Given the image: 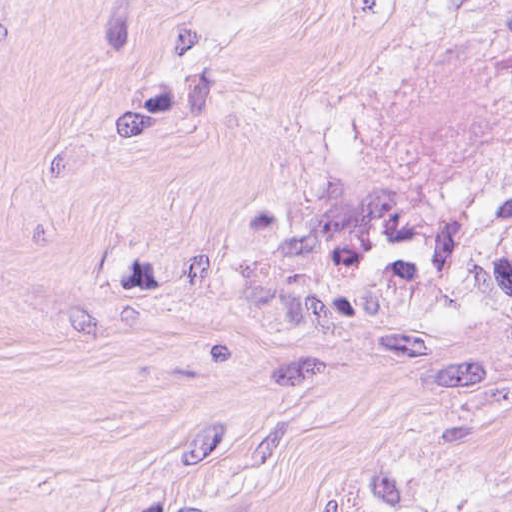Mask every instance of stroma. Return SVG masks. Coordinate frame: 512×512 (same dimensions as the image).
<instances>
[{"label": "stroma", "instance_id": "1", "mask_svg": "<svg viewBox=\"0 0 512 512\" xmlns=\"http://www.w3.org/2000/svg\"><path fill=\"white\" fill-rule=\"evenodd\" d=\"M0 512H512V0H0Z\"/></svg>", "mask_w": 512, "mask_h": 512}]
</instances>
